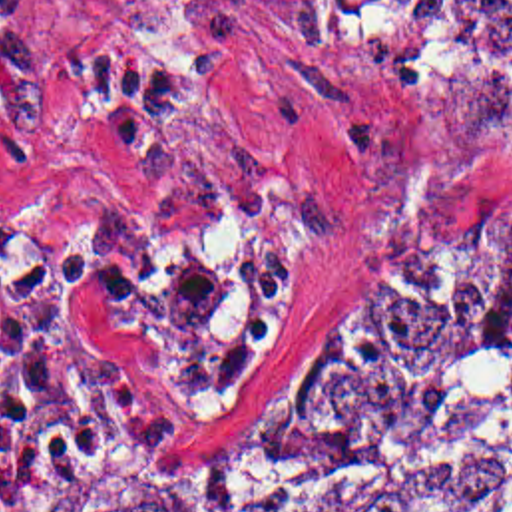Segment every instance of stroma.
<instances>
[{
  "instance_id": "stroma-1",
  "label": "stroma",
  "mask_w": 512,
  "mask_h": 512,
  "mask_svg": "<svg viewBox=\"0 0 512 512\" xmlns=\"http://www.w3.org/2000/svg\"><path fill=\"white\" fill-rule=\"evenodd\" d=\"M35 2L39 53L0 75V199L138 280L140 304L65 302L148 420L11 428L1 512L31 438L194 454L353 247L512 185V85L465 63L457 0Z\"/></svg>"
}]
</instances>
